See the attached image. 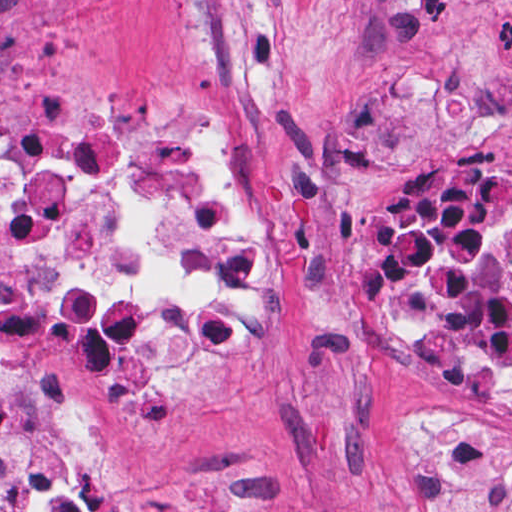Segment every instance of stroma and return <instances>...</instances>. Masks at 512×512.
Instances as JSON below:
<instances>
[{
  "label": "stroma",
  "mask_w": 512,
  "mask_h": 512,
  "mask_svg": "<svg viewBox=\"0 0 512 512\" xmlns=\"http://www.w3.org/2000/svg\"><path fill=\"white\" fill-rule=\"evenodd\" d=\"M158 101L265 197L257 320L178 396L87 384L32 323L0 321V362L106 434L118 512H431L410 411L512 427V401L366 339L365 263L414 170L512 167V0H0V111L110 129Z\"/></svg>",
  "instance_id": "stroma-1"
}]
</instances>
